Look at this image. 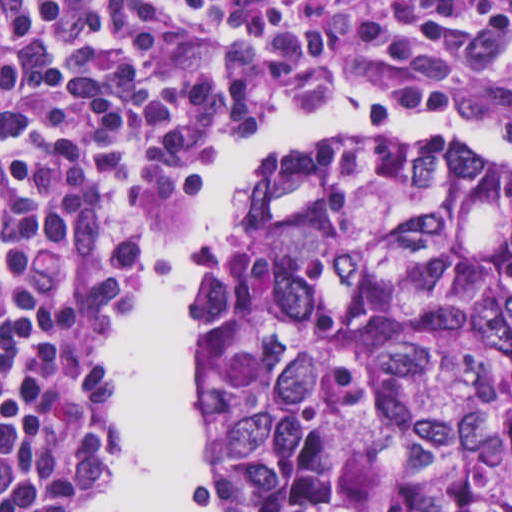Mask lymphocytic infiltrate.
Returning a JSON list of instances; mask_svg holds the SVG:
<instances>
[{
  "label": "lymphocytic infiltrate",
  "mask_w": 512,
  "mask_h": 512,
  "mask_svg": "<svg viewBox=\"0 0 512 512\" xmlns=\"http://www.w3.org/2000/svg\"><path fill=\"white\" fill-rule=\"evenodd\" d=\"M331 95L512 138V1H0V512L111 487L105 339L179 185Z\"/></svg>",
  "instance_id": "obj_1"
}]
</instances>
